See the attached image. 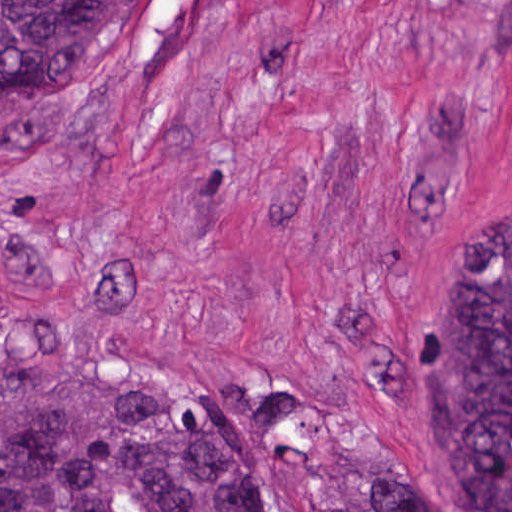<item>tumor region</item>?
<instances>
[{"label": "tumor region", "instance_id": "1", "mask_svg": "<svg viewBox=\"0 0 512 512\" xmlns=\"http://www.w3.org/2000/svg\"><path fill=\"white\" fill-rule=\"evenodd\" d=\"M157 0H0V89L120 45ZM158 369L0 372V512H259L252 455L317 512H425L334 425L211 349ZM428 453L461 512H512V214L450 284Z\"/></svg>", "mask_w": 512, "mask_h": 512}]
</instances>
